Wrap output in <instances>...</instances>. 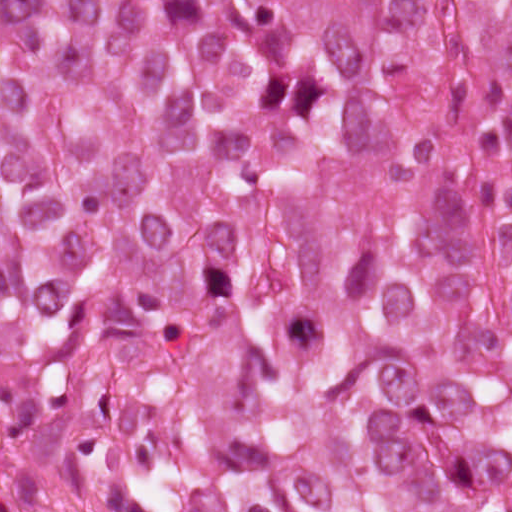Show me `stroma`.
Listing matches in <instances>:
<instances>
[{
	"label": "stroma",
	"mask_w": 512,
	"mask_h": 512,
	"mask_svg": "<svg viewBox=\"0 0 512 512\" xmlns=\"http://www.w3.org/2000/svg\"><path fill=\"white\" fill-rule=\"evenodd\" d=\"M0 512H41L33 479L19 459L1 445Z\"/></svg>",
	"instance_id": "stroma-1"
}]
</instances>
